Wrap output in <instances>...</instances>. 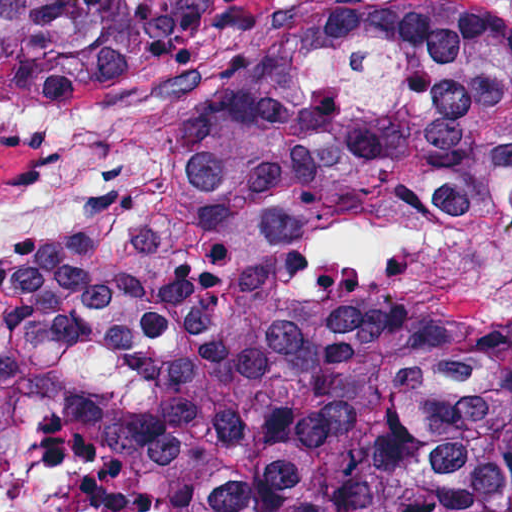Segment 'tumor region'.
Returning a JSON list of instances; mask_svg holds the SVG:
<instances>
[{"mask_svg":"<svg viewBox=\"0 0 512 512\" xmlns=\"http://www.w3.org/2000/svg\"><path fill=\"white\" fill-rule=\"evenodd\" d=\"M219 2L0 0V89L178 74ZM383 169H512V19L298 0L135 235L0 256V512H512V319L322 346L291 294V230Z\"/></svg>","mask_w":512,"mask_h":512,"instance_id":"e687c5a6","label":"tumor region"}]
</instances>
